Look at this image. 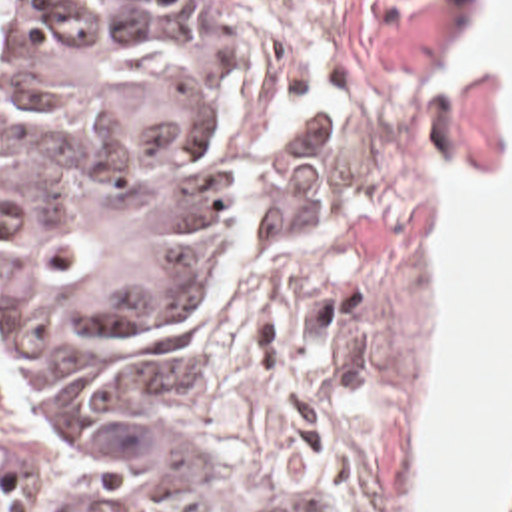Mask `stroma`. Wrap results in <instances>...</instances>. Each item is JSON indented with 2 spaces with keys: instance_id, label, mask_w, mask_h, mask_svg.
<instances>
[{
  "instance_id": "stroma-1",
  "label": "stroma",
  "mask_w": 512,
  "mask_h": 512,
  "mask_svg": "<svg viewBox=\"0 0 512 512\" xmlns=\"http://www.w3.org/2000/svg\"><path fill=\"white\" fill-rule=\"evenodd\" d=\"M211 1L269 139V211L247 269L165 343V399L233 511L409 512L438 181L506 179L502 71L446 77L486 0ZM0 512H75L1 309Z\"/></svg>"
}]
</instances>
